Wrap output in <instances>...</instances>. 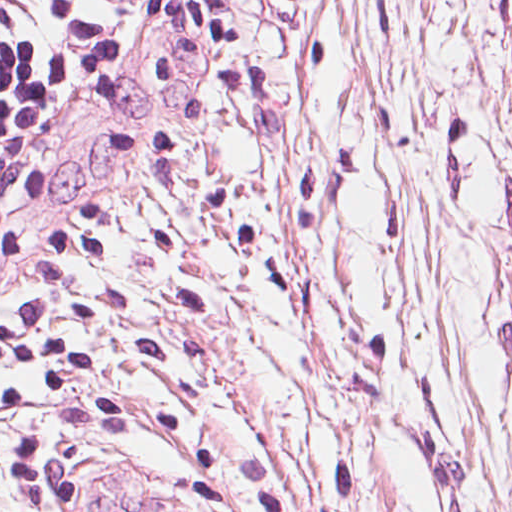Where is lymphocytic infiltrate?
Here are the masks:
<instances>
[{
    "label": "lymphocytic infiltrate",
    "instance_id": "obj_1",
    "mask_svg": "<svg viewBox=\"0 0 512 512\" xmlns=\"http://www.w3.org/2000/svg\"><path fill=\"white\" fill-rule=\"evenodd\" d=\"M88 33L85 0H0V210L25 174L43 102Z\"/></svg>",
    "mask_w": 512,
    "mask_h": 512
}]
</instances>
